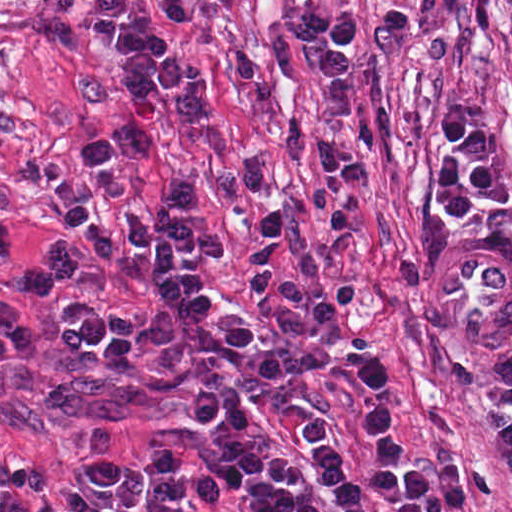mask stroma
I'll return each instance as SVG.
<instances>
[{"label":"stroma","mask_w":512,"mask_h":512,"mask_svg":"<svg viewBox=\"0 0 512 512\" xmlns=\"http://www.w3.org/2000/svg\"><path fill=\"white\" fill-rule=\"evenodd\" d=\"M92 1L0 0V195L23 248L37 253L59 238L122 229L124 208L148 220L175 182L188 181L200 195L192 225L229 249L217 262L190 259L186 272L213 304L216 323L240 317L258 350H275L285 363L282 388L261 390L238 371L236 356L227 358L257 418L256 432L240 441L281 448L329 512H343L309 465L301 423L314 419L342 442V474L364 494L365 512H394L366 478L374 458L366 411L343 383L368 352L389 371L393 433L409 462L422 474L461 464V512H512V477L493 456L485 417L512 394V0H491L485 27L468 26L465 0H243L234 15L198 0L180 23L163 0H141L198 65L212 109L189 127L149 109L146 156L110 163L94 216L72 231L47 194L70 173L81 143L119 126L126 111L112 50L83 38ZM295 8L362 20L341 127V141L364 163V181L351 193L323 184L317 130L328 91L302 62L310 45L287 30ZM466 100L494 128L508 206L476 196L468 216L442 219L428 195L436 121ZM268 205L290 221L284 263L292 282L309 293L337 280L351 285L349 307L311 335L274 328L255 309L248 261ZM133 253L142 281L102 267L82 275L77 291L108 309L162 314L148 280L155 255L138 243ZM63 298L25 293L0 268V300L21 311L36 341L56 338ZM96 423L111 428L123 459L141 466L165 449L205 470L196 458L214 440L211 426L189 420L182 375L111 379L82 359L0 373V443L52 468L43 500L59 511L70 507L62 490L99 489L88 462ZM209 473L226 509L245 512L235 489ZM119 512H152L144 487L135 506ZM179 512L204 511L187 503Z\"/></svg>","instance_id":"stroma-1"}]
</instances>
